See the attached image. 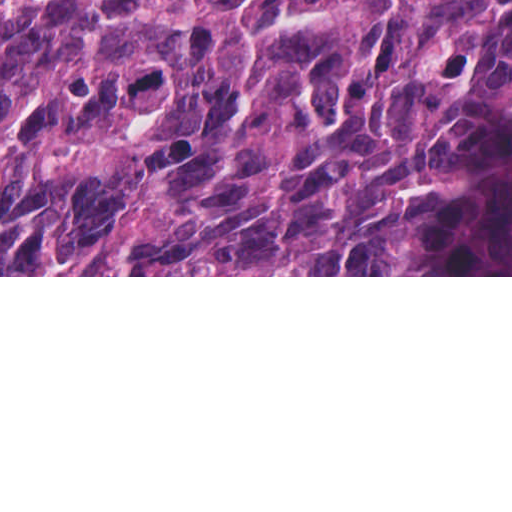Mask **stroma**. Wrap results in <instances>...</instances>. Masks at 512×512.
Masks as SVG:
<instances>
[{
	"mask_svg": "<svg viewBox=\"0 0 512 512\" xmlns=\"http://www.w3.org/2000/svg\"><path fill=\"white\" fill-rule=\"evenodd\" d=\"M512 4V0H510ZM0 277H512V275H0Z\"/></svg>",
	"mask_w": 512,
	"mask_h": 512,
	"instance_id": "35a3bbf8",
	"label": "stroma"
}]
</instances>
